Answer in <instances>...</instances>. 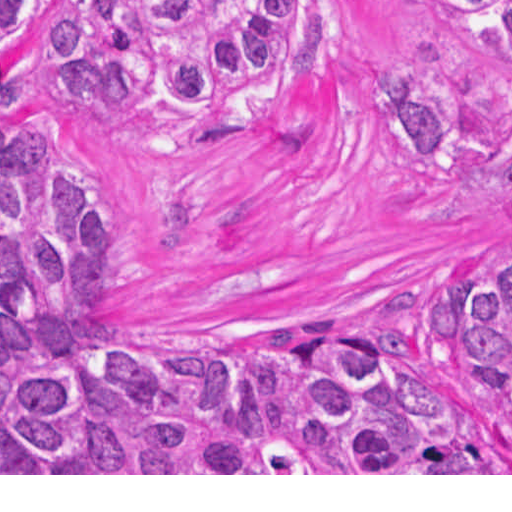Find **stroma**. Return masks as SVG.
I'll use <instances>...</instances> for the list:
<instances>
[{"label":"stroma","instance_id":"stroma-1","mask_svg":"<svg viewBox=\"0 0 512 512\" xmlns=\"http://www.w3.org/2000/svg\"><path fill=\"white\" fill-rule=\"evenodd\" d=\"M0 41V120L58 139L129 226L132 350L255 356L309 313L390 337L452 417L512 457L496 407L463 376L432 281L512 261V74L443 0H312L308 76L226 113L125 99L76 114L35 87L34 24ZM374 70L437 76L470 137L456 169H415L371 92ZM0 475H512V473H0Z\"/></svg>","mask_w":512,"mask_h":512}]
</instances>
